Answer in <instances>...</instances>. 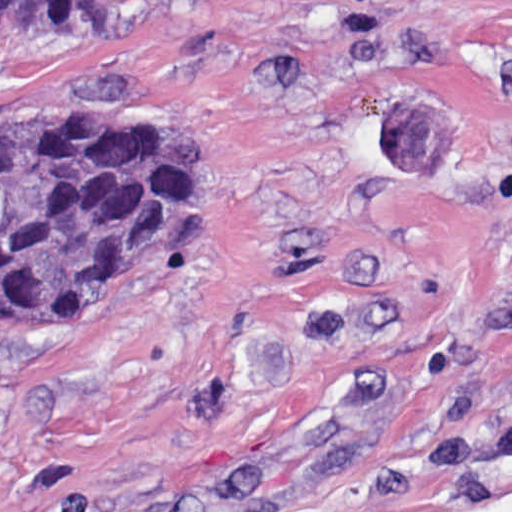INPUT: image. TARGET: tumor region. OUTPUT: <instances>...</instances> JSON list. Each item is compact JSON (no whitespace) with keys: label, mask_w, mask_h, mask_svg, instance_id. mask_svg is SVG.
<instances>
[{"label":"tumor region","mask_w":512,"mask_h":512,"mask_svg":"<svg viewBox=\"0 0 512 512\" xmlns=\"http://www.w3.org/2000/svg\"><path fill=\"white\" fill-rule=\"evenodd\" d=\"M150 0H0V60L77 22ZM201 190L193 129L128 118L0 120V326L98 307L135 289Z\"/></svg>","instance_id":"tumor-region-1"}]
</instances>
